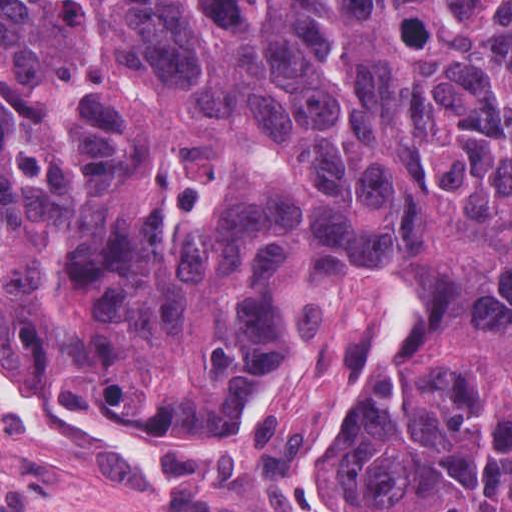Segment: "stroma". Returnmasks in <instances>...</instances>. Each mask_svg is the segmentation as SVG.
<instances>
[{"mask_svg":"<svg viewBox=\"0 0 512 512\" xmlns=\"http://www.w3.org/2000/svg\"><path fill=\"white\" fill-rule=\"evenodd\" d=\"M406 272L346 253L319 266L310 318L238 437L156 433L34 378L1 349L0 512H373L320 461L321 407L358 350L398 323Z\"/></svg>","mask_w":512,"mask_h":512,"instance_id":"35a3bbf8","label":"stroma"}]
</instances>
